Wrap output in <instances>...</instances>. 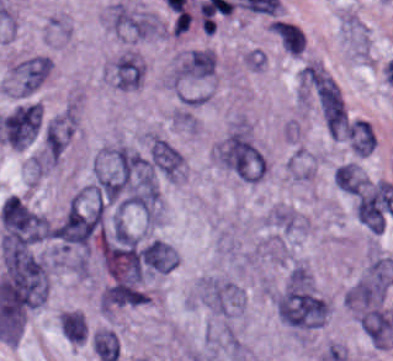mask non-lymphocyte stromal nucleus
<instances>
[{"mask_svg": "<svg viewBox=\"0 0 393 361\" xmlns=\"http://www.w3.org/2000/svg\"><path fill=\"white\" fill-rule=\"evenodd\" d=\"M108 26L120 37L133 40L158 39L162 23L156 13L117 2L108 7Z\"/></svg>", "mask_w": 393, "mask_h": 361, "instance_id": "obj_4", "label": "non-lymphocyte stromal nucleus"}, {"mask_svg": "<svg viewBox=\"0 0 393 361\" xmlns=\"http://www.w3.org/2000/svg\"><path fill=\"white\" fill-rule=\"evenodd\" d=\"M144 79V62L133 49H125L109 65V81L123 92L139 89Z\"/></svg>", "mask_w": 393, "mask_h": 361, "instance_id": "obj_8", "label": "non-lymphocyte stromal nucleus"}, {"mask_svg": "<svg viewBox=\"0 0 393 361\" xmlns=\"http://www.w3.org/2000/svg\"><path fill=\"white\" fill-rule=\"evenodd\" d=\"M144 156L155 173L177 181L183 175V157L167 139L153 132L145 134Z\"/></svg>", "mask_w": 393, "mask_h": 361, "instance_id": "obj_7", "label": "non-lymphocyte stromal nucleus"}, {"mask_svg": "<svg viewBox=\"0 0 393 361\" xmlns=\"http://www.w3.org/2000/svg\"><path fill=\"white\" fill-rule=\"evenodd\" d=\"M51 59L33 55L11 67L8 92L19 98H29L44 83L50 74Z\"/></svg>", "mask_w": 393, "mask_h": 361, "instance_id": "obj_6", "label": "non-lymphocyte stromal nucleus"}, {"mask_svg": "<svg viewBox=\"0 0 393 361\" xmlns=\"http://www.w3.org/2000/svg\"><path fill=\"white\" fill-rule=\"evenodd\" d=\"M59 323L62 336L67 341L82 345L87 327L81 312L77 310H61Z\"/></svg>", "mask_w": 393, "mask_h": 361, "instance_id": "obj_11", "label": "non-lymphocyte stromal nucleus"}, {"mask_svg": "<svg viewBox=\"0 0 393 361\" xmlns=\"http://www.w3.org/2000/svg\"><path fill=\"white\" fill-rule=\"evenodd\" d=\"M309 79L325 130L331 137H339L346 126V114L338 85L320 67L311 68Z\"/></svg>", "mask_w": 393, "mask_h": 361, "instance_id": "obj_5", "label": "non-lymphocyte stromal nucleus"}, {"mask_svg": "<svg viewBox=\"0 0 393 361\" xmlns=\"http://www.w3.org/2000/svg\"><path fill=\"white\" fill-rule=\"evenodd\" d=\"M93 349L100 361H116L120 344L116 334L107 328H99L93 335Z\"/></svg>", "mask_w": 393, "mask_h": 361, "instance_id": "obj_12", "label": "non-lymphocyte stromal nucleus"}, {"mask_svg": "<svg viewBox=\"0 0 393 361\" xmlns=\"http://www.w3.org/2000/svg\"><path fill=\"white\" fill-rule=\"evenodd\" d=\"M270 32L286 52L297 56L302 53L304 34L298 25L275 20Z\"/></svg>", "mask_w": 393, "mask_h": 361, "instance_id": "obj_10", "label": "non-lymphocyte stromal nucleus"}, {"mask_svg": "<svg viewBox=\"0 0 393 361\" xmlns=\"http://www.w3.org/2000/svg\"><path fill=\"white\" fill-rule=\"evenodd\" d=\"M214 157L240 180L257 183L265 178L266 158L251 130L233 129L216 143Z\"/></svg>", "mask_w": 393, "mask_h": 361, "instance_id": "obj_1", "label": "non-lymphocyte stromal nucleus"}, {"mask_svg": "<svg viewBox=\"0 0 393 361\" xmlns=\"http://www.w3.org/2000/svg\"><path fill=\"white\" fill-rule=\"evenodd\" d=\"M393 284V262L370 261L344 293L353 316L385 303Z\"/></svg>", "mask_w": 393, "mask_h": 361, "instance_id": "obj_2", "label": "non-lymphocyte stromal nucleus"}, {"mask_svg": "<svg viewBox=\"0 0 393 361\" xmlns=\"http://www.w3.org/2000/svg\"><path fill=\"white\" fill-rule=\"evenodd\" d=\"M336 184L347 194L358 196L368 185V178L355 162H347L334 173Z\"/></svg>", "mask_w": 393, "mask_h": 361, "instance_id": "obj_9", "label": "non-lymphocyte stromal nucleus"}, {"mask_svg": "<svg viewBox=\"0 0 393 361\" xmlns=\"http://www.w3.org/2000/svg\"><path fill=\"white\" fill-rule=\"evenodd\" d=\"M278 320L294 331L316 329L327 317L329 304L319 292L280 289L275 294Z\"/></svg>", "mask_w": 393, "mask_h": 361, "instance_id": "obj_3", "label": "non-lymphocyte stromal nucleus"}]
</instances>
